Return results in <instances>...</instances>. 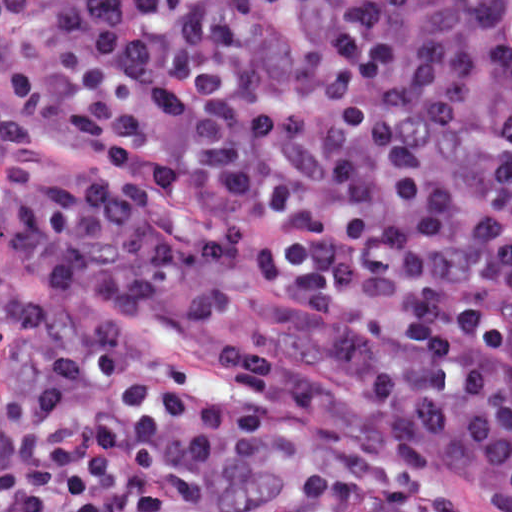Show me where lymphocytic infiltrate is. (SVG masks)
Listing matches in <instances>:
<instances>
[{"instance_id": "1", "label": "lymphocytic infiltrate", "mask_w": 512, "mask_h": 512, "mask_svg": "<svg viewBox=\"0 0 512 512\" xmlns=\"http://www.w3.org/2000/svg\"><path fill=\"white\" fill-rule=\"evenodd\" d=\"M0 237L321 369L225 385L0 266V512H512V0H0Z\"/></svg>"}]
</instances>
